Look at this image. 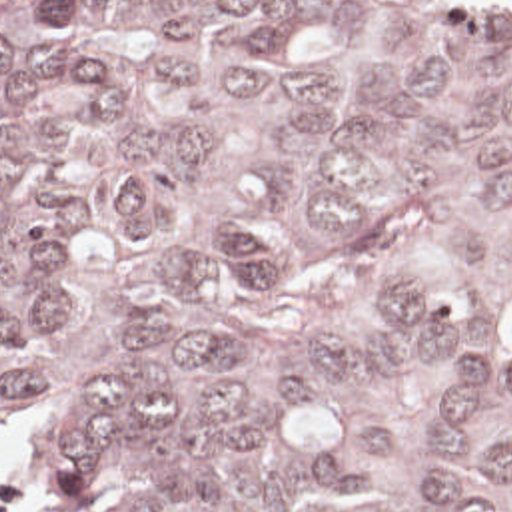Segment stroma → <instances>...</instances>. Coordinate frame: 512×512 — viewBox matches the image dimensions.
I'll return each instance as SVG.
<instances>
[{
	"label": "stroma",
	"mask_w": 512,
	"mask_h": 512,
	"mask_svg": "<svg viewBox=\"0 0 512 512\" xmlns=\"http://www.w3.org/2000/svg\"><path fill=\"white\" fill-rule=\"evenodd\" d=\"M0 468L24 478L22 512H40V448L24 421L0 430Z\"/></svg>",
	"instance_id": "stroma-1"
}]
</instances>
